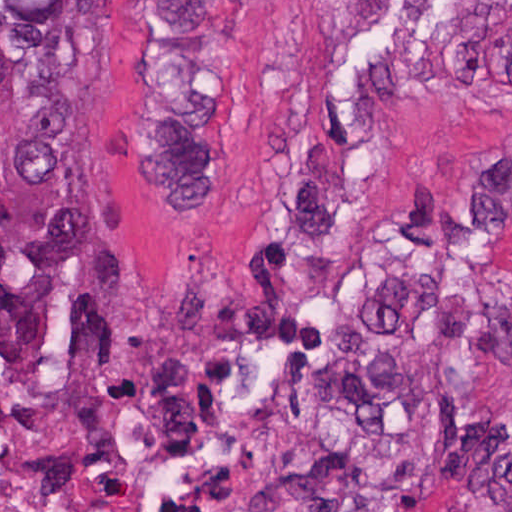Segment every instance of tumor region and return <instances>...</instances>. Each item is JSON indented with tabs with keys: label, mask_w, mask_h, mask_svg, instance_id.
<instances>
[{
	"label": "tumor region",
	"mask_w": 512,
	"mask_h": 512,
	"mask_svg": "<svg viewBox=\"0 0 512 512\" xmlns=\"http://www.w3.org/2000/svg\"><path fill=\"white\" fill-rule=\"evenodd\" d=\"M153 183L209 200L221 172L227 0H156ZM133 354L78 65V0H0V377L83 384Z\"/></svg>",
	"instance_id": "1"
}]
</instances>
